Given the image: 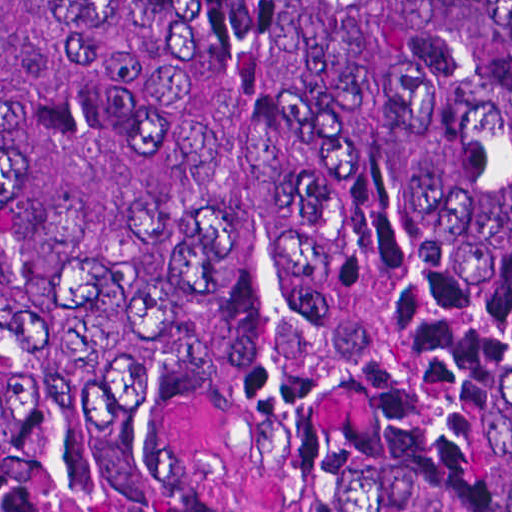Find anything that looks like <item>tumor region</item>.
Segmentation results:
<instances>
[{
	"mask_svg": "<svg viewBox=\"0 0 512 512\" xmlns=\"http://www.w3.org/2000/svg\"><path fill=\"white\" fill-rule=\"evenodd\" d=\"M0 510L512 512V0H0Z\"/></svg>",
	"mask_w": 512,
	"mask_h": 512,
	"instance_id": "tumor-region-1",
	"label": "tumor region"
}]
</instances>
